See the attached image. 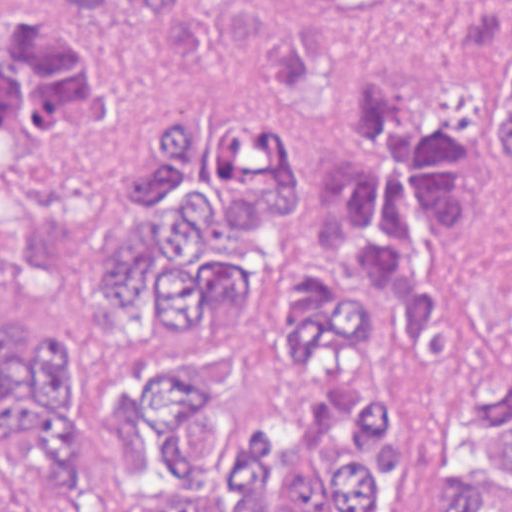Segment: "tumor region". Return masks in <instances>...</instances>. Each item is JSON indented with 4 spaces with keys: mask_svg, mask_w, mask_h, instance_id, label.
I'll list each match as a JSON object with an SVG mask.
<instances>
[{
    "mask_svg": "<svg viewBox=\"0 0 512 512\" xmlns=\"http://www.w3.org/2000/svg\"><path fill=\"white\" fill-rule=\"evenodd\" d=\"M99 22L120 0H55ZM207 0H135L171 17ZM512 21V0H442L440 35ZM478 101L512 176V43ZM115 95L88 38L30 20L0 39V179L19 152L99 135ZM476 128L383 77L332 89L317 183L255 116L184 120L127 196L143 237L95 280L173 369L120 401V466L100 470L77 368L36 309L0 301V512H392L412 439L431 512H512V351L475 362L448 268L476 233Z\"/></svg>",
    "mask_w": 512,
    "mask_h": 512,
    "instance_id": "1",
    "label": "tumor region"
}]
</instances>
